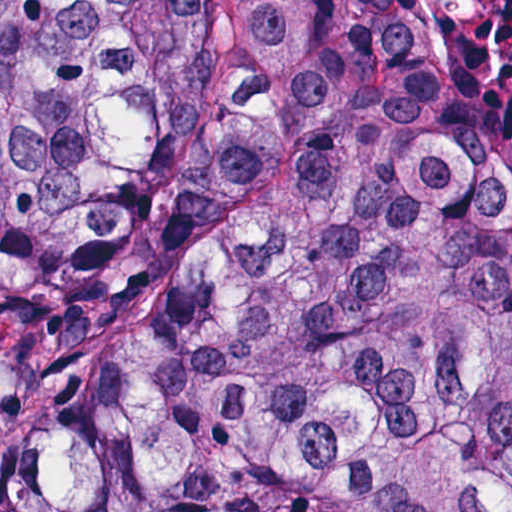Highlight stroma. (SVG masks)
Here are the masks:
<instances>
[{"label": "stroma", "instance_id": "35a3bbf8", "mask_svg": "<svg viewBox=\"0 0 512 512\" xmlns=\"http://www.w3.org/2000/svg\"><path fill=\"white\" fill-rule=\"evenodd\" d=\"M388 7L394 10L397 14H399L402 18H404L407 22H409L412 26L418 29L421 33H423L426 37L429 38L422 21L420 19L419 13L412 2V0H381ZM430 39V38H429ZM431 42V41H430ZM432 44V43H431ZM433 46V45H432ZM434 48V47H433ZM435 50V49H434ZM436 52V51H435ZM437 54V52H436ZM438 56V54H437ZM439 58V56H438ZM451 84H453L461 102L488 112L492 115L505 119L507 121L512 122V103H495L489 102L473 93L466 87H464L453 75H451L445 68L441 59L439 58Z\"/></svg>", "mask_w": 512, "mask_h": 512}]
</instances>
